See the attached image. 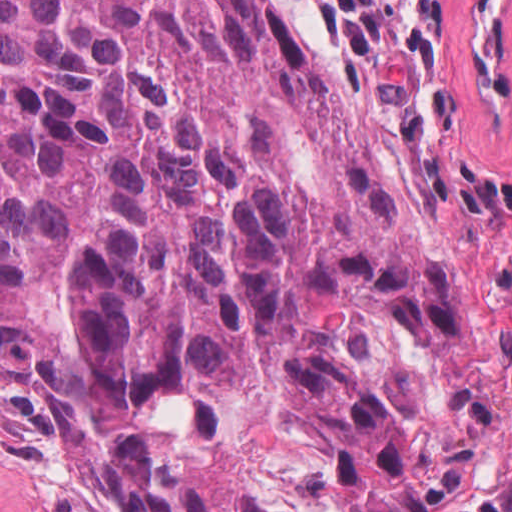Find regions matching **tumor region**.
<instances>
[{
  "label": "tumor region",
  "instance_id": "obj_1",
  "mask_svg": "<svg viewBox=\"0 0 512 512\" xmlns=\"http://www.w3.org/2000/svg\"><path fill=\"white\" fill-rule=\"evenodd\" d=\"M0 381L99 512H463L495 336L267 0H0Z\"/></svg>",
  "mask_w": 512,
  "mask_h": 512
}]
</instances>
